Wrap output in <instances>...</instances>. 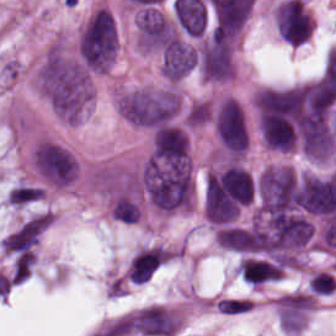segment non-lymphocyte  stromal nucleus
Here are the masks:
<instances>
[{
	"instance_id": "dd21d789",
	"label": "non-lymphocyte stromal nucleus",
	"mask_w": 336,
	"mask_h": 336,
	"mask_svg": "<svg viewBox=\"0 0 336 336\" xmlns=\"http://www.w3.org/2000/svg\"><path fill=\"white\" fill-rule=\"evenodd\" d=\"M253 302L247 298H221L216 306L221 314H241L251 309Z\"/></svg>"
}]
</instances>
